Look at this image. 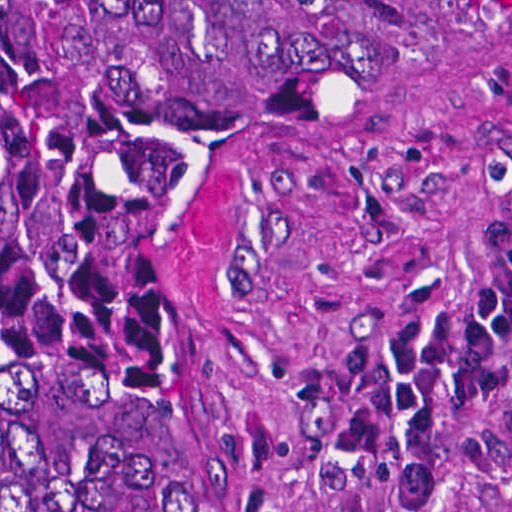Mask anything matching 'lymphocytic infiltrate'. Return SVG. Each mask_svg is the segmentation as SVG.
I'll return each instance as SVG.
<instances>
[{
	"instance_id": "obj_1",
	"label": "lymphocytic infiltrate",
	"mask_w": 512,
	"mask_h": 512,
	"mask_svg": "<svg viewBox=\"0 0 512 512\" xmlns=\"http://www.w3.org/2000/svg\"><path fill=\"white\" fill-rule=\"evenodd\" d=\"M512 337V244L468 299L450 312L414 317L389 339L378 383L328 432L329 453L356 467L367 501L424 509L435 492V412L439 391L466 402L491 397L496 348Z\"/></svg>"
}]
</instances>
